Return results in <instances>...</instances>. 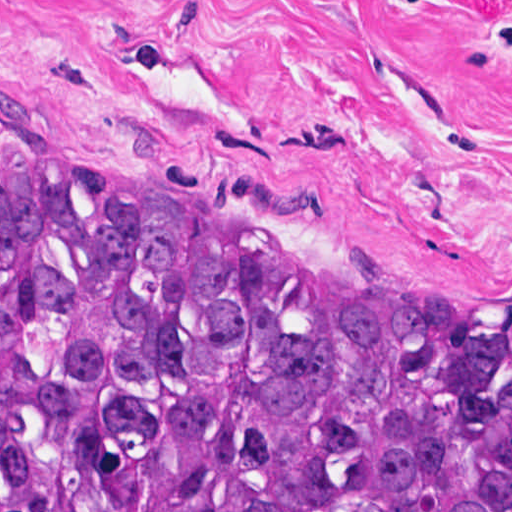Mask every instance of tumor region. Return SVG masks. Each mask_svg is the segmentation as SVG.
Returning a JSON list of instances; mask_svg holds the SVG:
<instances>
[{"instance_id": "1", "label": "tumor region", "mask_w": 512, "mask_h": 512, "mask_svg": "<svg viewBox=\"0 0 512 512\" xmlns=\"http://www.w3.org/2000/svg\"><path fill=\"white\" fill-rule=\"evenodd\" d=\"M269 233L0 174V512H512V340Z\"/></svg>"}]
</instances>
